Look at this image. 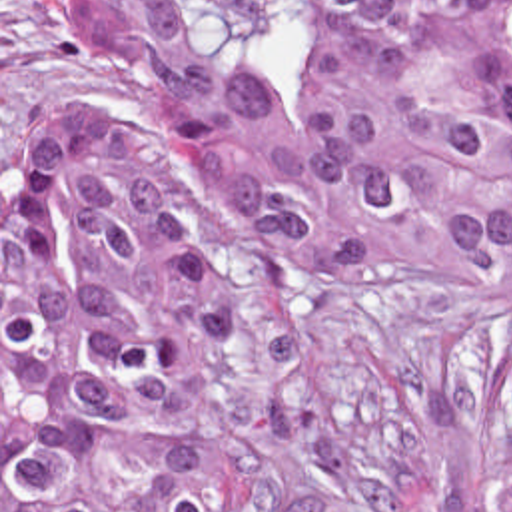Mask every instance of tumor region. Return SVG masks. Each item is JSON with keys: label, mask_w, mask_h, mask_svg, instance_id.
I'll return each instance as SVG.
<instances>
[{"label": "tumor region", "mask_w": 512, "mask_h": 512, "mask_svg": "<svg viewBox=\"0 0 512 512\" xmlns=\"http://www.w3.org/2000/svg\"><path fill=\"white\" fill-rule=\"evenodd\" d=\"M48 7L92 79L126 53L172 151L78 103L8 137L2 512H256L216 438L226 217L284 281L435 271L485 303L481 512H512V0Z\"/></svg>", "instance_id": "obj_1"}]
</instances>
